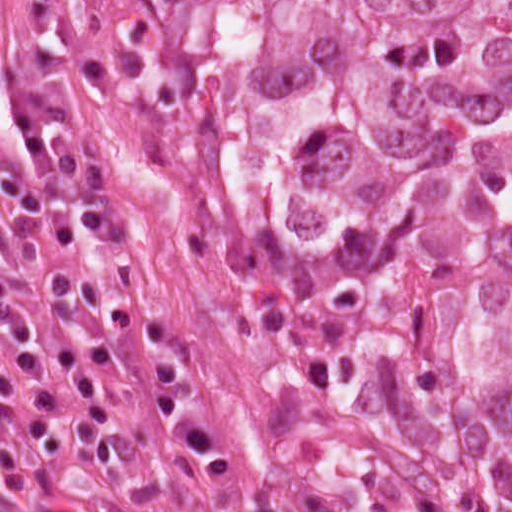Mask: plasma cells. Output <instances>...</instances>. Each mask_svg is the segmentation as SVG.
Masks as SVG:
<instances>
[{"label": "plasma cells", "mask_w": 512, "mask_h": 512, "mask_svg": "<svg viewBox=\"0 0 512 512\" xmlns=\"http://www.w3.org/2000/svg\"><path fill=\"white\" fill-rule=\"evenodd\" d=\"M14 112L26 141L21 174H0V193L13 207L10 227L21 242L14 267L0 263V322L13 337L25 392L38 404L62 411L79 434L70 437L42 412L25 419L27 436L37 447L80 473L104 475L130 454L134 438L97 377V367L109 371L124 401L146 418L171 445L201 461L212 472L226 470L230 459L211 422L189 395L184 380V341L169 323L108 298L83 272L61 268L52 273L47 300L64 319L91 310L112 323L148 339L154 347L161 397L147 400L125 387L110 347L85 341L55 349L63 373L80 390L87 408L78 413L50 374L40 352L38 331L19 298L21 284L44 261L42 240L54 246L70 244L76 235L71 215L48 200L49 172L59 174L81 205L82 221L93 235L122 231L107 189V177L92 157L57 151L55 139L74 125L78 111L68 101H38L17 82L0 81V107ZM19 391L14 372L0 361V399ZM250 487L201 512H289L275 497L250 482ZM0 512H116L60 481L44 468L0 421Z\"/></svg>", "instance_id": "obj_1"}]
</instances>
